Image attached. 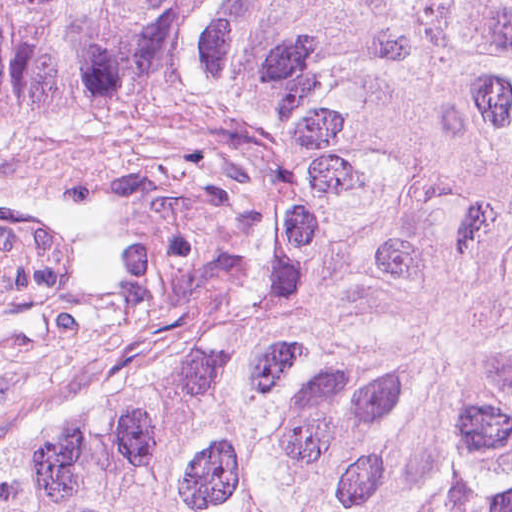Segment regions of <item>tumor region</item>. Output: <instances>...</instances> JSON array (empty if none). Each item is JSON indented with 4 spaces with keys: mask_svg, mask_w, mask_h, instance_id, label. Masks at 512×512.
Listing matches in <instances>:
<instances>
[{
    "mask_svg": "<svg viewBox=\"0 0 512 512\" xmlns=\"http://www.w3.org/2000/svg\"><path fill=\"white\" fill-rule=\"evenodd\" d=\"M221 139L250 336L0 445V512H512V0H0V148Z\"/></svg>",
    "mask_w": 512,
    "mask_h": 512,
    "instance_id": "1",
    "label": "tumor region"
}]
</instances>
